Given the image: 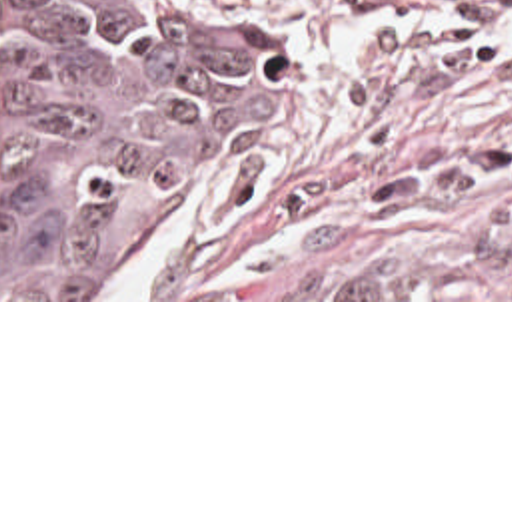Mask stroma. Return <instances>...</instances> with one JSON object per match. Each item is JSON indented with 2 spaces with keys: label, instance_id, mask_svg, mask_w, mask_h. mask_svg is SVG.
Wrapping results in <instances>:
<instances>
[{
  "label": "stroma",
  "instance_id": "stroma-1",
  "mask_svg": "<svg viewBox=\"0 0 512 512\" xmlns=\"http://www.w3.org/2000/svg\"><path fill=\"white\" fill-rule=\"evenodd\" d=\"M278 100L178 202L146 298L512 302V0H262ZM170 216V218H172Z\"/></svg>",
  "mask_w": 512,
  "mask_h": 512
}]
</instances>
